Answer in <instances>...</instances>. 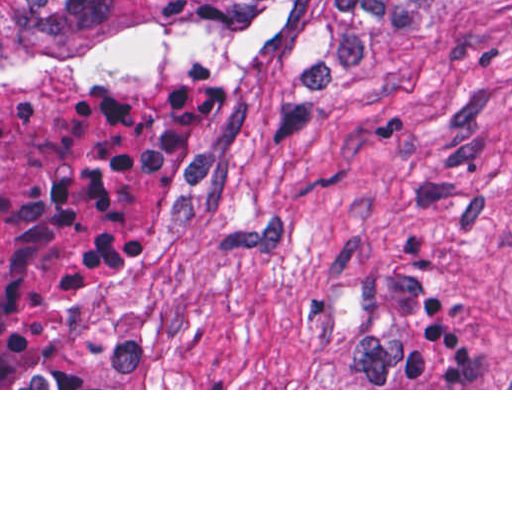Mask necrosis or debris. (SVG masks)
Instances as JSON below:
<instances>
[{
	"label": "necrosis or debris",
	"instance_id": "4bbe7bcc",
	"mask_svg": "<svg viewBox=\"0 0 512 512\" xmlns=\"http://www.w3.org/2000/svg\"><path fill=\"white\" fill-rule=\"evenodd\" d=\"M245 114L204 83L49 90L0 109V388H86L63 335L167 218L220 206Z\"/></svg>",
	"mask_w": 512,
	"mask_h": 512
}]
</instances>
